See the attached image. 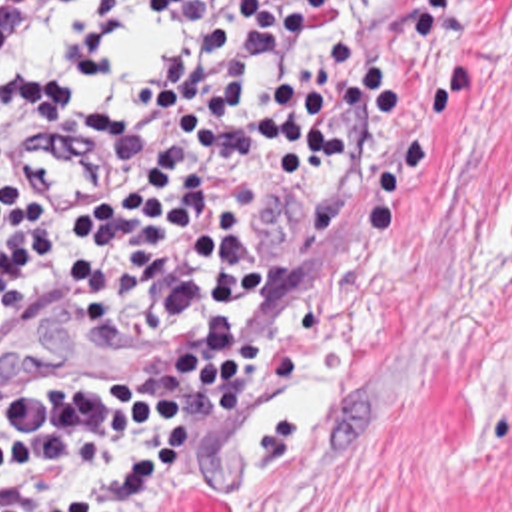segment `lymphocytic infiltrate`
<instances>
[{"label": "lymphocytic infiltrate", "instance_id": "1", "mask_svg": "<svg viewBox=\"0 0 512 512\" xmlns=\"http://www.w3.org/2000/svg\"><path fill=\"white\" fill-rule=\"evenodd\" d=\"M395 119L343 0H0V355L53 311L229 333L269 273L239 247L269 211L271 147H367ZM43 123L121 149L101 209L19 207L13 155ZM265 345L235 331L177 377H0V512L139 511Z\"/></svg>", "mask_w": 512, "mask_h": 512}]
</instances>
